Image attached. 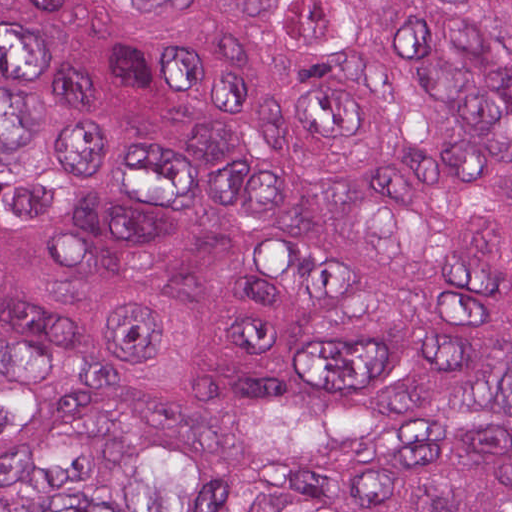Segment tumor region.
<instances>
[{
  "label": "tumor region",
  "instance_id": "e687c5a6",
  "mask_svg": "<svg viewBox=\"0 0 512 512\" xmlns=\"http://www.w3.org/2000/svg\"><path fill=\"white\" fill-rule=\"evenodd\" d=\"M0 512H512V0H0Z\"/></svg>",
  "mask_w": 512,
  "mask_h": 512
}]
</instances>
